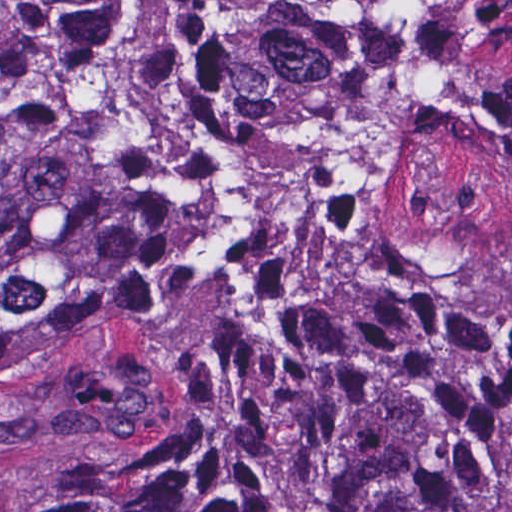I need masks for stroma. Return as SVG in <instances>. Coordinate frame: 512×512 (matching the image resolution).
Here are the masks:
<instances>
[{
	"mask_svg": "<svg viewBox=\"0 0 512 512\" xmlns=\"http://www.w3.org/2000/svg\"><path fill=\"white\" fill-rule=\"evenodd\" d=\"M6 16L0 0V53ZM198 429L142 355L80 347L0 379V512H39L94 476L179 449Z\"/></svg>",
	"mask_w": 512,
	"mask_h": 512,
	"instance_id": "obj_1",
	"label": "stroma"
}]
</instances>
